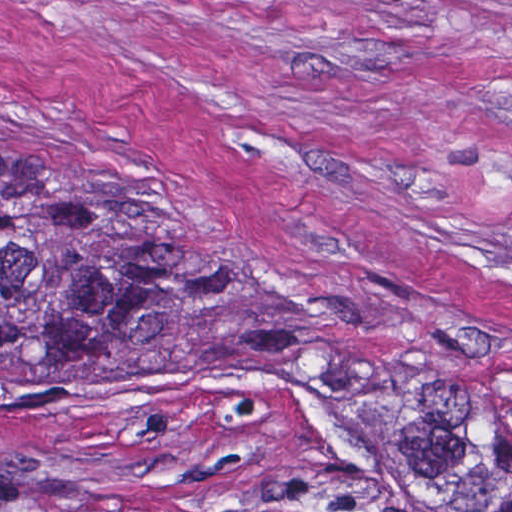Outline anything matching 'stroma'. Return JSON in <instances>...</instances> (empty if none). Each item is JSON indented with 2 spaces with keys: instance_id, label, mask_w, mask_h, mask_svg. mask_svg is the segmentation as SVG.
<instances>
[{
  "instance_id": "1",
  "label": "stroma",
  "mask_w": 512,
  "mask_h": 512,
  "mask_svg": "<svg viewBox=\"0 0 512 512\" xmlns=\"http://www.w3.org/2000/svg\"><path fill=\"white\" fill-rule=\"evenodd\" d=\"M56 188L234 316L123 380L0 359V512H422L304 342L512 391V0H0V200Z\"/></svg>"
}]
</instances>
